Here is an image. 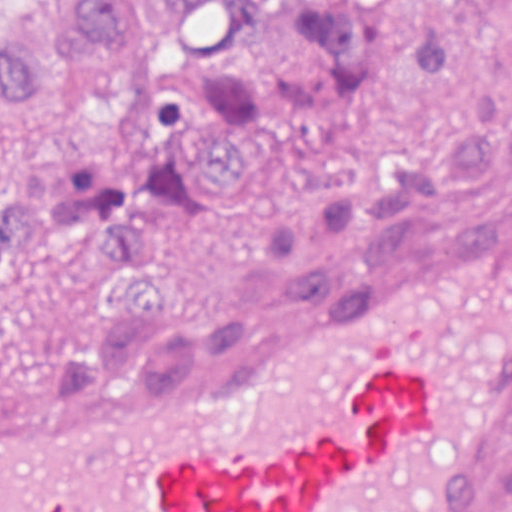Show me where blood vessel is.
I'll list each match as a JSON object with an SVG mask.
<instances>
[{
    "mask_svg": "<svg viewBox=\"0 0 512 512\" xmlns=\"http://www.w3.org/2000/svg\"><path fill=\"white\" fill-rule=\"evenodd\" d=\"M512 433V219L0 377V512H466Z\"/></svg>",
    "mask_w": 512,
    "mask_h": 512,
    "instance_id": "blood-vessel-1",
    "label": "blood vessel"
}]
</instances>
